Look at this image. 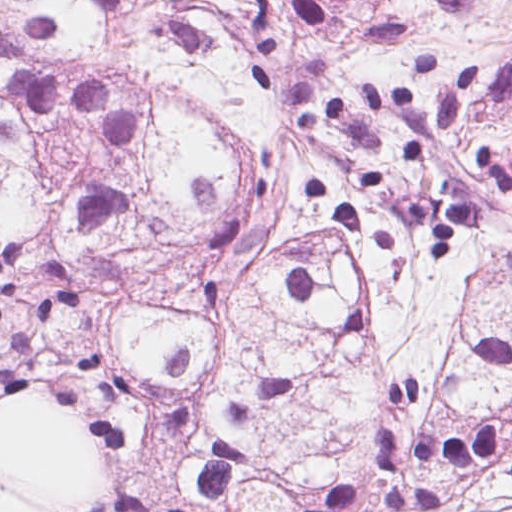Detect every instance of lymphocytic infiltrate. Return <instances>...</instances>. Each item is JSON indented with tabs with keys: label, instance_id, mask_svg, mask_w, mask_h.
I'll list each match as a JSON object with an SVG mask.
<instances>
[{
	"label": "lymphocytic infiltrate",
	"instance_id": "obj_1",
	"mask_svg": "<svg viewBox=\"0 0 512 512\" xmlns=\"http://www.w3.org/2000/svg\"><path fill=\"white\" fill-rule=\"evenodd\" d=\"M485 457L498 459L512 474V451L502 440L492 419L480 421L473 430L447 432L405 449L392 432L386 436L381 452L382 473L392 475L411 459L430 466H468ZM360 489L334 487L305 506L304 512H340L358 501Z\"/></svg>",
	"mask_w": 512,
	"mask_h": 512
}]
</instances>
